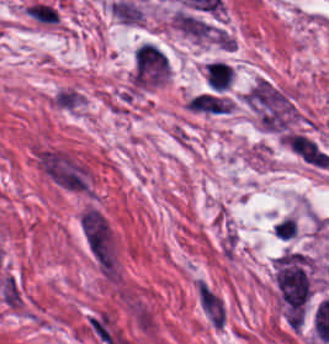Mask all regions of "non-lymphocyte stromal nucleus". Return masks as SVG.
<instances>
[{"label":"non-lymphocyte stromal nucleus","mask_w":329,"mask_h":344,"mask_svg":"<svg viewBox=\"0 0 329 344\" xmlns=\"http://www.w3.org/2000/svg\"><path fill=\"white\" fill-rule=\"evenodd\" d=\"M283 142L290 152L314 167H327L329 154L315 139L305 132L289 131Z\"/></svg>","instance_id":"81446118"},{"label":"non-lymphocyte stromal nucleus","mask_w":329,"mask_h":344,"mask_svg":"<svg viewBox=\"0 0 329 344\" xmlns=\"http://www.w3.org/2000/svg\"><path fill=\"white\" fill-rule=\"evenodd\" d=\"M199 307L207 323L214 329H225L230 309L223 292L205 277L194 282Z\"/></svg>","instance_id":"fc2b8d12"},{"label":"non-lymphocyte stromal nucleus","mask_w":329,"mask_h":344,"mask_svg":"<svg viewBox=\"0 0 329 344\" xmlns=\"http://www.w3.org/2000/svg\"><path fill=\"white\" fill-rule=\"evenodd\" d=\"M1 293L3 302L18 306L20 300V289L18 283L10 275H5L1 279Z\"/></svg>","instance_id":"9d01c50a"},{"label":"non-lymphocyte stromal nucleus","mask_w":329,"mask_h":344,"mask_svg":"<svg viewBox=\"0 0 329 344\" xmlns=\"http://www.w3.org/2000/svg\"><path fill=\"white\" fill-rule=\"evenodd\" d=\"M40 171L64 191L95 196V177L91 164L70 149L56 145L40 149Z\"/></svg>","instance_id":"dd21d789"},{"label":"non-lymphocyte stromal nucleus","mask_w":329,"mask_h":344,"mask_svg":"<svg viewBox=\"0 0 329 344\" xmlns=\"http://www.w3.org/2000/svg\"><path fill=\"white\" fill-rule=\"evenodd\" d=\"M186 105L193 111L210 113H224L231 107L229 101L224 97L205 92H198L193 95Z\"/></svg>","instance_id":"7c5642bf"},{"label":"non-lymphocyte stromal nucleus","mask_w":329,"mask_h":344,"mask_svg":"<svg viewBox=\"0 0 329 344\" xmlns=\"http://www.w3.org/2000/svg\"><path fill=\"white\" fill-rule=\"evenodd\" d=\"M77 231L91 260L98 266L115 264V235L109 219L91 203L77 213Z\"/></svg>","instance_id":"a72fc3eb"},{"label":"non-lymphocyte stromal nucleus","mask_w":329,"mask_h":344,"mask_svg":"<svg viewBox=\"0 0 329 344\" xmlns=\"http://www.w3.org/2000/svg\"><path fill=\"white\" fill-rule=\"evenodd\" d=\"M170 73V58L164 49L150 42H143L138 47L133 59L132 85L149 88L163 84Z\"/></svg>","instance_id":"3746e769"}]
</instances>
